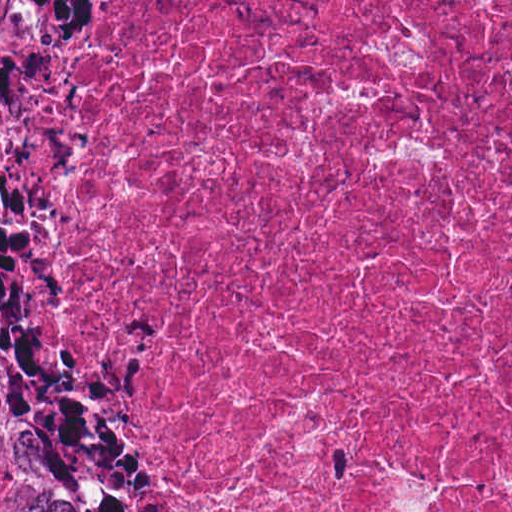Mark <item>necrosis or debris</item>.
<instances>
[{
    "mask_svg": "<svg viewBox=\"0 0 512 512\" xmlns=\"http://www.w3.org/2000/svg\"><path fill=\"white\" fill-rule=\"evenodd\" d=\"M63 399L125 512H512V0H136Z\"/></svg>",
    "mask_w": 512,
    "mask_h": 512,
    "instance_id": "necrosis-or-debris-1",
    "label": "necrosis or debris"
}]
</instances>
